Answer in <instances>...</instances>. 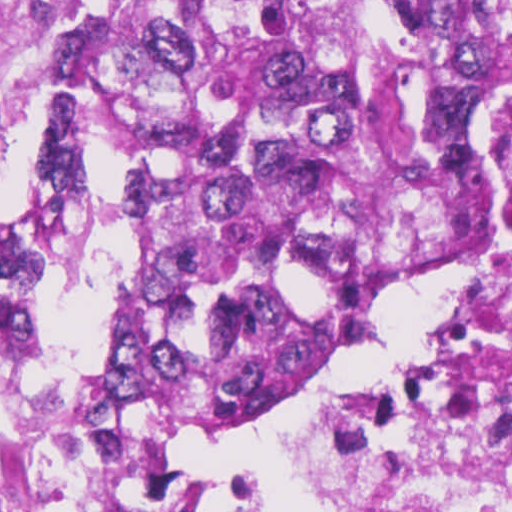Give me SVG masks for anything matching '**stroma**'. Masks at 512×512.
<instances>
[{
    "mask_svg": "<svg viewBox=\"0 0 512 512\" xmlns=\"http://www.w3.org/2000/svg\"><path fill=\"white\" fill-rule=\"evenodd\" d=\"M492 1L453 0V63L441 137L407 170L309 326L283 374L271 412L239 438L272 436V423L336 363L347 299L387 219L433 180L469 112L495 91L490 85ZM50 12L49 0H0V127L31 116L47 132V148L67 100L51 99L42 79ZM315 435L300 437L307 450ZM185 490L187 512H235L241 494L209 490L201 476Z\"/></svg>",
    "mask_w": 512,
    "mask_h": 512,
    "instance_id": "stroma-1",
    "label": "stroma"
}]
</instances>
